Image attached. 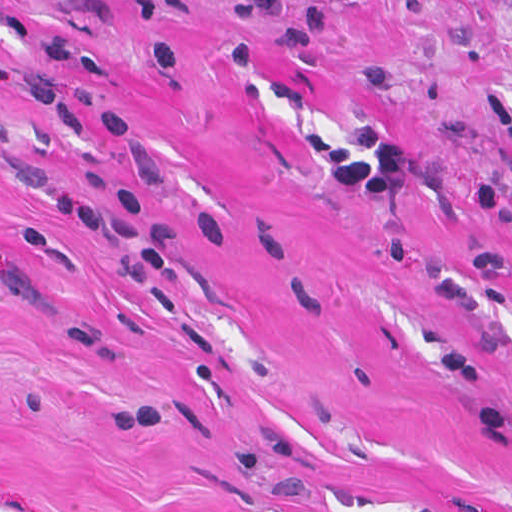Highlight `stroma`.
Here are the masks:
<instances>
[{"label": "stroma", "instance_id": "stroma-1", "mask_svg": "<svg viewBox=\"0 0 512 512\" xmlns=\"http://www.w3.org/2000/svg\"><path fill=\"white\" fill-rule=\"evenodd\" d=\"M480 188L512 0H0V512H512Z\"/></svg>", "mask_w": 512, "mask_h": 512}]
</instances>
